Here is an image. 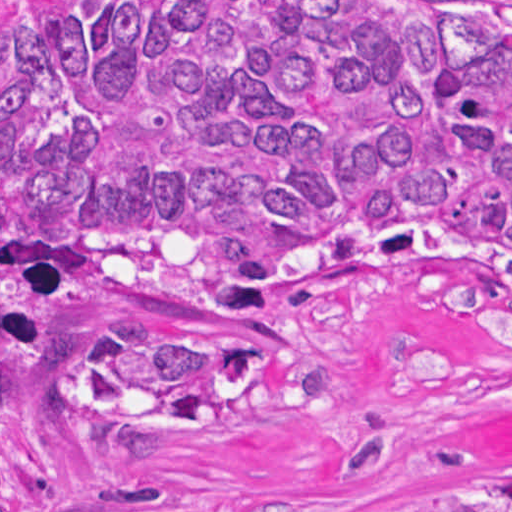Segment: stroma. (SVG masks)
<instances>
[{
    "label": "stroma",
    "mask_w": 512,
    "mask_h": 512,
    "mask_svg": "<svg viewBox=\"0 0 512 512\" xmlns=\"http://www.w3.org/2000/svg\"><path fill=\"white\" fill-rule=\"evenodd\" d=\"M512 465V352L410 295L340 292L295 333L292 365L188 428H95L80 468L0 512H405Z\"/></svg>",
    "instance_id": "stroma-1"
}]
</instances>
